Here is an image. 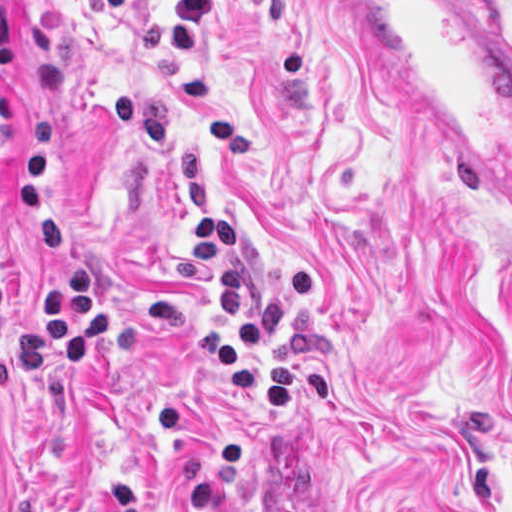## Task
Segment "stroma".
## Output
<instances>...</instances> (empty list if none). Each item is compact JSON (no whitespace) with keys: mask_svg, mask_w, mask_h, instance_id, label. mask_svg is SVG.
Listing matches in <instances>:
<instances>
[{"mask_svg":"<svg viewBox=\"0 0 512 512\" xmlns=\"http://www.w3.org/2000/svg\"><path fill=\"white\" fill-rule=\"evenodd\" d=\"M497 1L512 24V0ZM1 308L36 312L22 160L49 116L73 236L113 304L74 376L0 349V512H512V231L473 201L339 0H0ZM232 220L267 342L333 402L255 403L204 220Z\"/></svg>","mask_w":512,"mask_h":512,"instance_id":"obj_1","label":"stroma"}]
</instances>
